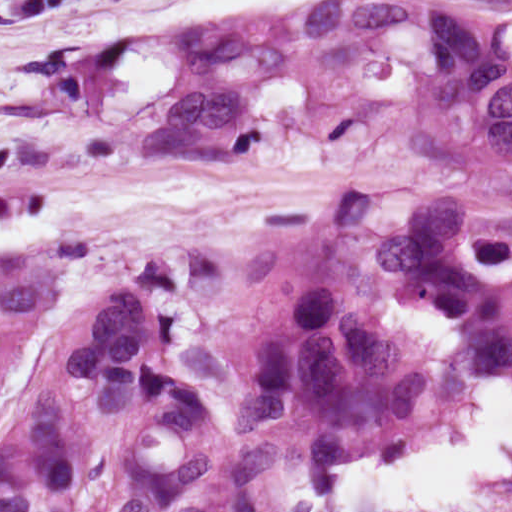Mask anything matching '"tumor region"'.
I'll return each mask as SVG.
<instances>
[{
	"instance_id": "1",
	"label": "tumor region",
	"mask_w": 512,
	"mask_h": 512,
	"mask_svg": "<svg viewBox=\"0 0 512 512\" xmlns=\"http://www.w3.org/2000/svg\"><path fill=\"white\" fill-rule=\"evenodd\" d=\"M458 370L480 382H512V344ZM137 512H301V503L284 501L274 450Z\"/></svg>"
}]
</instances>
